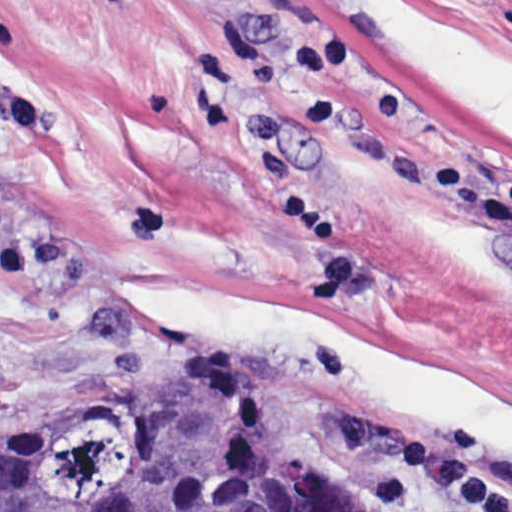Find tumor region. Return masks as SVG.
Returning <instances> with one entry per match:
<instances>
[{"label":"tumor region","instance_id":"e687c5a6","mask_svg":"<svg viewBox=\"0 0 512 512\" xmlns=\"http://www.w3.org/2000/svg\"><path fill=\"white\" fill-rule=\"evenodd\" d=\"M0 512H365L270 390L134 401L0 454Z\"/></svg>","mask_w":512,"mask_h":512}]
</instances>
